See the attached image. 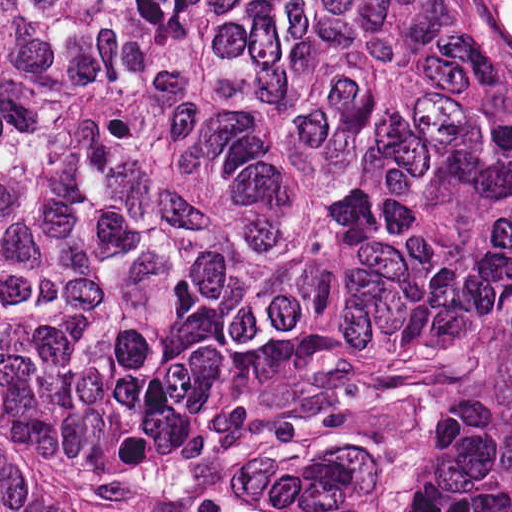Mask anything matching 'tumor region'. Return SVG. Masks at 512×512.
I'll use <instances>...</instances> for the list:
<instances>
[{
	"instance_id": "e687c5a6",
	"label": "tumor region",
	"mask_w": 512,
	"mask_h": 512,
	"mask_svg": "<svg viewBox=\"0 0 512 512\" xmlns=\"http://www.w3.org/2000/svg\"><path fill=\"white\" fill-rule=\"evenodd\" d=\"M512 214L509 64L313 0H0V512L11 440L129 512H365L256 449L412 413Z\"/></svg>"
}]
</instances>
